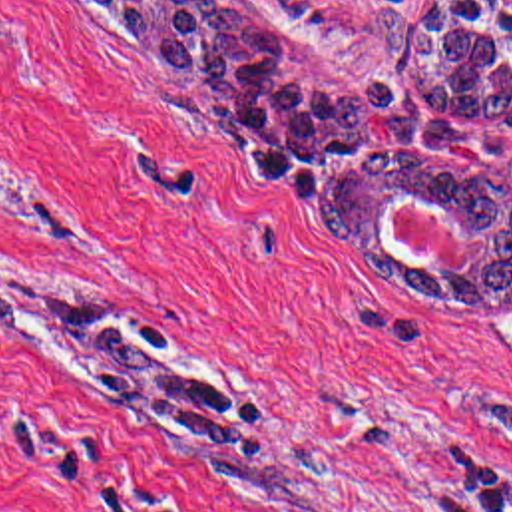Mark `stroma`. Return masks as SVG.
Segmentation results:
<instances>
[{
	"mask_svg": "<svg viewBox=\"0 0 512 512\" xmlns=\"http://www.w3.org/2000/svg\"><path fill=\"white\" fill-rule=\"evenodd\" d=\"M224 1L332 97L425 101L380 13L407 31L433 0ZM393 214L419 268L467 264L433 202ZM3 276L119 312L256 425L182 449L93 395L103 360L0 336V512H457L512 479V298L385 286L89 0H0Z\"/></svg>",
	"mask_w": 512,
	"mask_h": 512,
	"instance_id": "stroma-1",
	"label": "stroma"
}]
</instances>
